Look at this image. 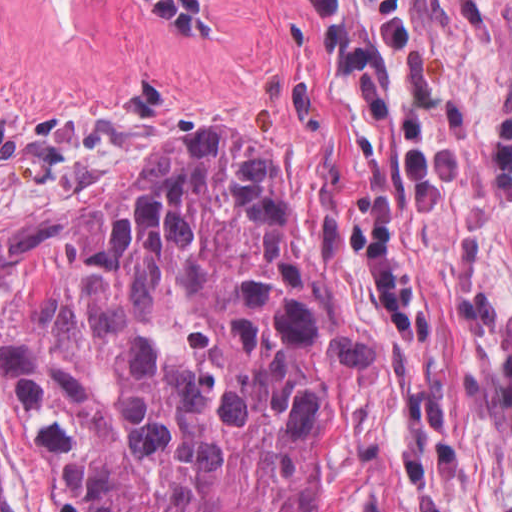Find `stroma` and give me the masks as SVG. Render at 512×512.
I'll return each mask as SVG.
<instances>
[{
	"label": "stroma",
	"instance_id": "35a3bbf8",
	"mask_svg": "<svg viewBox=\"0 0 512 512\" xmlns=\"http://www.w3.org/2000/svg\"><path fill=\"white\" fill-rule=\"evenodd\" d=\"M98 1L178 140L233 135L278 158L338 299L392 366L374 478L393 511L512 512V0H403L406 52L345 0L392 108H421L459 148L431 213L300 0H198L210 34Z\"/></svg>",
	"mask_w": 512,
	"mask_h": 512
}]
</instances>
